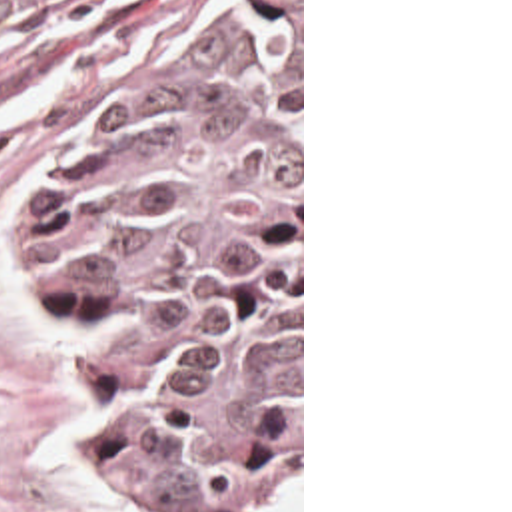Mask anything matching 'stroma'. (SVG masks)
Here are the masks:
<instances>
[{"mask_svg": "<svg viewBox=\"0 0 512 512\" xmlns=\"http://www.w3.org/2000/svg\"><path fill=\"white\" fill-rule=\"evenodd\" d=\"M252 0H70L0 41V512H182L112 473L86 335L36 269L32 213L78 141L154 57ZM304 512V0H300V461L270 512Z\"/></svg>", "mask_w": 512, "mask_h": 512, "instance_id": "1", "label": "stroma"}]
</instances>
